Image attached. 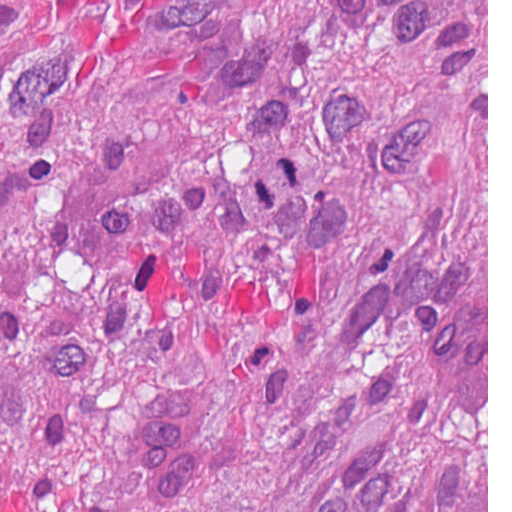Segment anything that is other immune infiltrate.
I'll use <instances>...</instances> for the list:
<instances>
[{
	"mask_svg": "<svg viewBox=\"0 0 512 512\" xmlns=\"http://www.w3.org/2000/svg\"><path fill=\"white\" fill-rule=\"evenodd\" d=\"M427 366L437 360L444 392L461 420L487 411L485 351L476 333L475 311L452 281L431 287L424 304ZM203 417L201 388L155 397L139 424L141 463L162 500L182 496L188 478L190 444Z\"/></svg>",
	"mask_w": 512,
	"mask_h": 512,
	"instance_id": "obj_1",
	"label": "other immune infiltrate"
}]
</instances>
